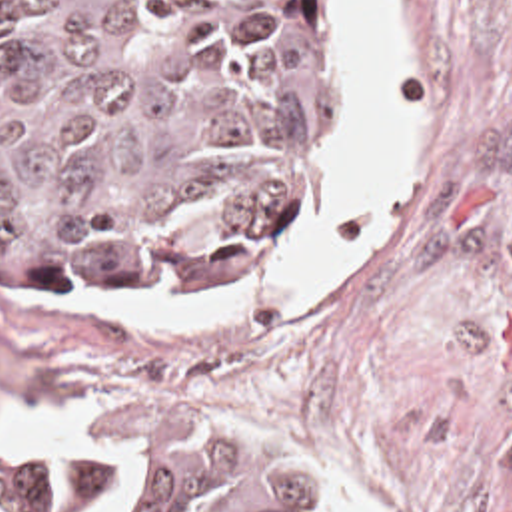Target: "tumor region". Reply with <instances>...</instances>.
I'll return each mask as SVG.
<instances>
[{"label": "tumor region", "instance_id": "obj_1", "mask_svg": "<svg viewBox=\"0 0 512 512\" xmlns=\"http://www.w3.org/2000/svg\"><path fill=\"white\" fill-rule=\"evenodd\" d=\"M371 197L345 1L0 0V283L19 297L277 281ZM27 502L345 512L287 438L193 403L135 405L45 450Z\"/></svg>", "mask_w": 512, "mask_h": 512}]
</instances>
